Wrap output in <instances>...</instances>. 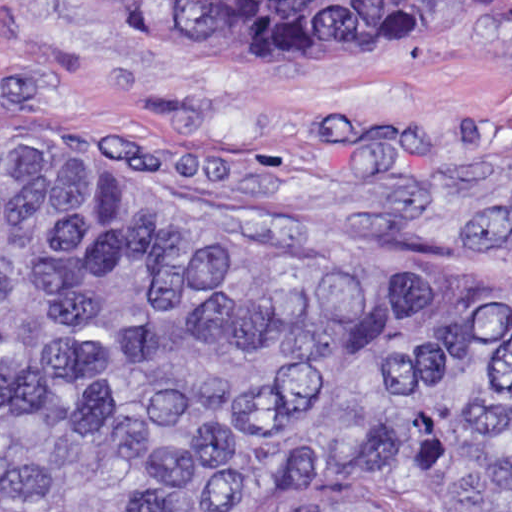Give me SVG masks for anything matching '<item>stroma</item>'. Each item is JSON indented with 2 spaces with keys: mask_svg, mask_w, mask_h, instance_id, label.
Listing matches in <instances>:
<instances>
[{
  "mask_svg": "<svg viewBox=\"0 0 512 512\" xmlns=\"http://www.w3.org/2000/svg\"><path fill=\"white\" fill-rule=\"evenodd\" d=\"M512 105V20L444 9L374 52L149 31L106 0H0V144L87 140L182 180L398 211L421 188L321 169L303 111Z\"/></svg>",
  "mask_w": 512,
  "mask_h": 512,
  "instance_id": "35a3bbf8",
  "label": "stroma"
}]
</instances>
